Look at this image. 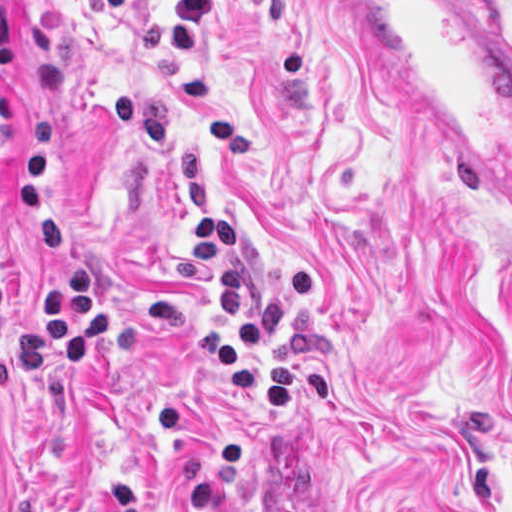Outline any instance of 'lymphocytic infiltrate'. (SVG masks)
I'll list each match as a JSON object with an SVG mask.
<instances>
[{
	"label": "lymphocytic infiltrate",
	"mask_w": 512,
	"mask_h": 512,
	"mask_svg": "<svg viewBox=\"0 0 512 512\" xmlns=\"http://www.w3.org/2000/svg\"><path fill=\"white\" fill-rule=\"evenodd\" d=\"M11 134V105L0 93V153ZM22 214L41 244V272L36 283V312L31 320L6 316L1 308L0 349L10 338L32 339L43 346L48 372L74 376L89 354L113 344V304L91 262L78 246L58 199L51 162L49 116L36 119L32 141L22 160ZM239 236L223 216L198 224L187 256L212 266L211 301L233 322L238 339L256 360L250 367L234 340L209 337L196 342L210 357L215 373L234 392L255 403H294L301 394L333 402L324 380L309 368L278 372L267 361V342L283 327L287 302L310 290L309 274H292L272 299L251 307L236 289L234 254Z\"/></svg>",
	"instance_id": "obj_1"
}]
</instances>
